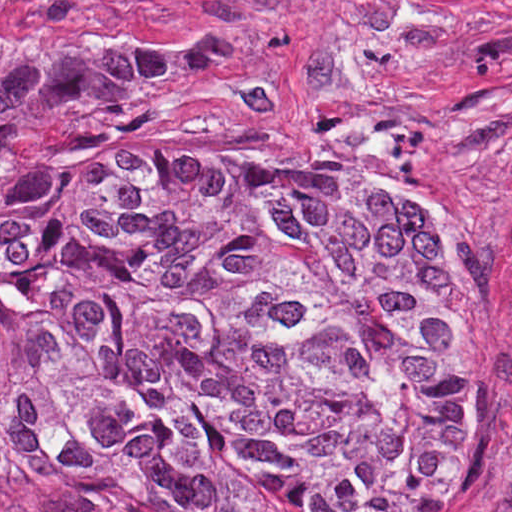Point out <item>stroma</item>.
<instances>
[{
  "label": "stroma",
  "instance_id": "35a3bbf8",
  "mask_svg": "<svg viewBox=\"0 0 512 512\" xmlns=\"http://www.w3.org/2000/svg\"><path fill=\"white\" fill-rule=\"evenodd\" d=\"M287 13L298 68L200 121L182 154L267 149L366 187L442 193L475 238L417 243L401 266L455 302V484L419 512H512V0H0V33L179 46ZM0 512H341L103 473L0 476Z\"/></svg>",
  "mask_w": 512,
  "mask_h": 512
}]
</instances>
